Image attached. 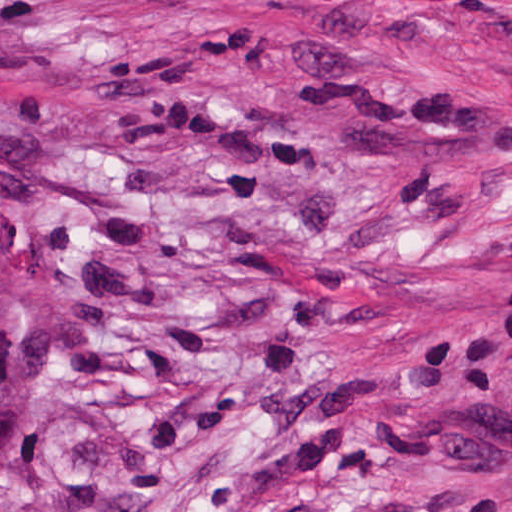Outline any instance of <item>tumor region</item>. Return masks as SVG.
Segmentation results:
<instances>
[{
  "label": "tumor region",
  "mask_w": 512,
  "mask_h": 512,
  "mask_svg": "<svg viewBox=\"0 0 512 512\" xmlns=\"http://www.w3.org/2000/svg\"><path fill=\"white\" fill-rule=\"evenodd\" d=\"M27 374V236L20 197L0 169V403Z\"/></svg>",
  "instance_id": "1"
}]
</instances>
